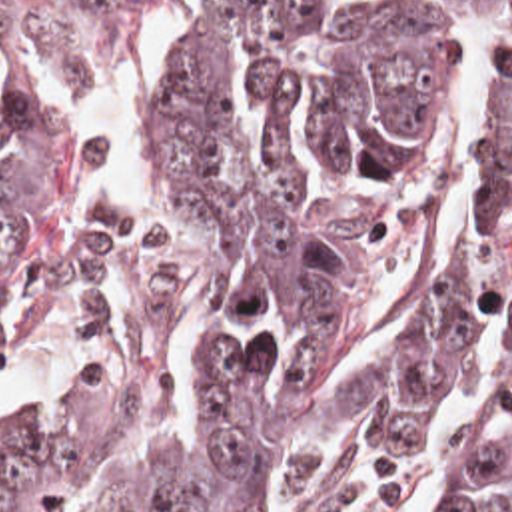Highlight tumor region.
<instances>
[{
  "mask_svg": "<svg viewBox=\"0 0 512 512\" xmlns=\"http://www.w3.org/2000/svg\"><path fill=\"white\" fill-rule=\"evenodd\" d=\"M147 0H71L127 22ZM496 26L484 196L414 318L333 380L368 288L434 212L464 74ZM161 210L73 242L57 122L0 0V362L77 316L93 374L0 436V512H410L420 448L492 316L496 382L434 512H512V0L343 18L199 0L153 86Z\"/></svg>",
  "mask_w": 512,
  "mask_h": 512,
  "instance_id": "1",
  "label": "tumor region"
}]
</instances>
